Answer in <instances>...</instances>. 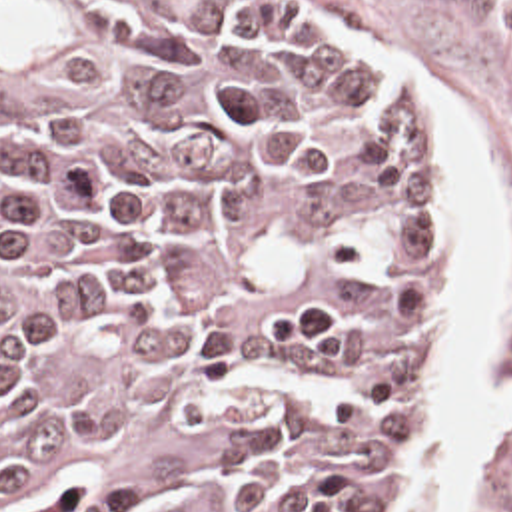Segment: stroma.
Here are the masks:
<instances>
[{
    "instance_id": "stroma-1",
    "label": "stroma",
    "mask_w": 512,
    "mask_h": 512,
    "mask_svg": "<svg viewBox=\"0 0 512 512\" xmlns=\"http://www.w3.org/2000/svg\"><path fill=\"white\" fill-rule=\"evenodd\" d=\"M86 12H122L152 0H34ZM320 30L352 70L409 100L439 134V246L437 282L427 300V330L413 378L411 404L394 491L384 512L398 505L406 487L415 430L425 406V372L453 264L449 244V156L445 134L425 100L390 82L370 54L330 26L338 22L380 36L407 70L437 72L477 124L512 202V0H270ZM512 384V324L505 340L501 386ZM479 512H512V426L487 458L479 480Z\"/></svg>"
}]
</instances>
